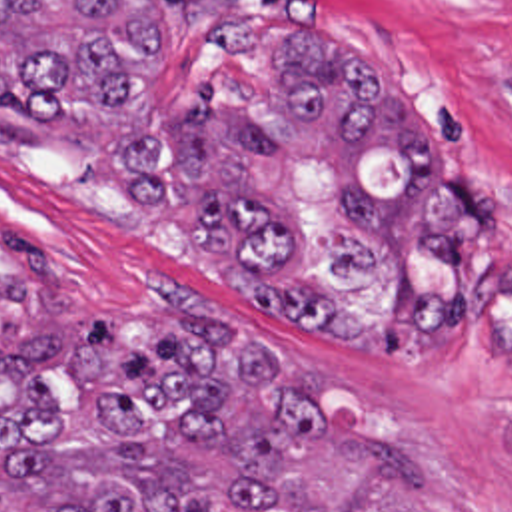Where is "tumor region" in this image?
I'll list each match as a JSON object with an SVG mask.
<instances>
[{"mask_svg":"<svg viewBox=\"0 0 512 512\" xmlns=\"http://www.w3.org/2000/svg\"><path fill=\"white\" fill-rule=\"evenodd\" d=\"M272 117L216 85L128 137L142 207L198 209L188 247L250 309L336 343L456 341L484 197L436 155L422 107L302 27ZM162 81L140 0H0V143L116 117ZM48 299V297H46ZM512 458V412L496 420ZM0 512H440L420 458L322 395L260 323L172 295L124 331H76L0 279Z\"/></svg>","mask_w":512,"mask_h":512,"instance_id":"tumor-region-1","label":"tumor region"}]
</instances>
